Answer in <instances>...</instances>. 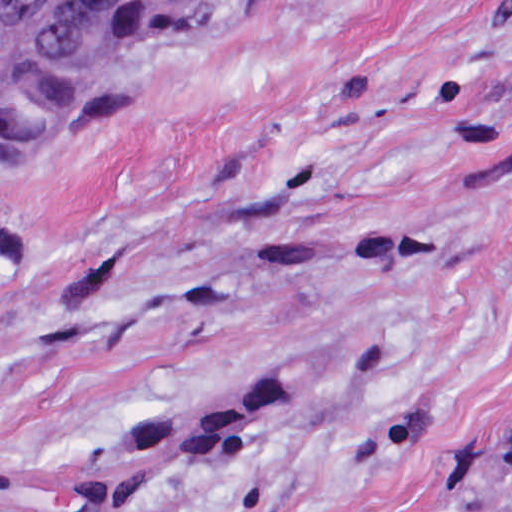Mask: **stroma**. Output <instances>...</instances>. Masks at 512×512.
I'll return each mask as SVG.
<instances>
[{
	"label": "stroma",
	"instance_id": "35a3bbf8",
	"mask_svg": "<svg viewBox=\"0 0 512 512\" xmlns=\"http://www.w3.org/2000/svg\"><path fill=\"white\" fill-rule=\"evenodd\" d=\"M511 446L512 0H214L0 152V512H481Z\"/></svg>",
	"mask_w": 512,
	"mask_h": 512
}]
</instances>
